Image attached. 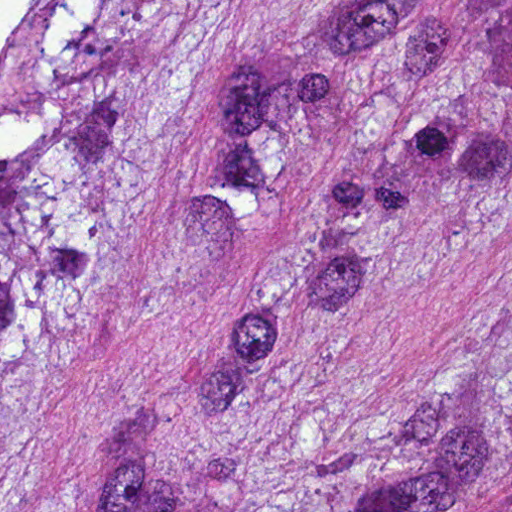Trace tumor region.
I'll return each mask as SVG.
<instances>
[{
    "mask_svg": "<svg viewBox=\"0 0 512 512\" xmlns=\"http://www.w3.org/2000/svg\"><path fill=\"white\" fill-rule=\"evenodd\" d=\"M235 0H0V512H22L119 229ZM512 198V1L351 0L234 78L211 209L259 250L221 398H267L327 331ZM103 512H512V344L413 413L243 466L149 423Z\"/></svg>",
    "mask_w": 512,
    "mask_h": 512,
    "instance_id": "obj_1",
    "label": "tumor region"
}]
</instances>
